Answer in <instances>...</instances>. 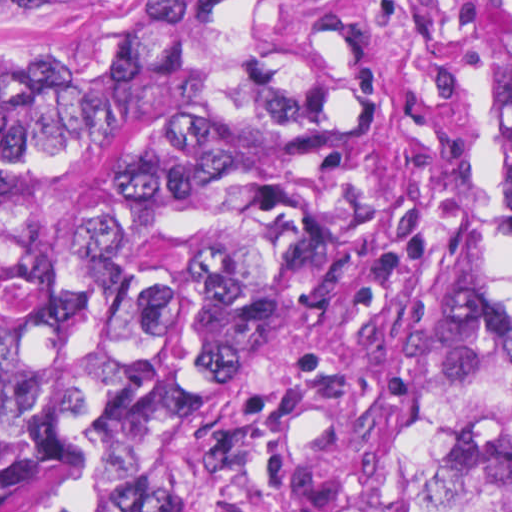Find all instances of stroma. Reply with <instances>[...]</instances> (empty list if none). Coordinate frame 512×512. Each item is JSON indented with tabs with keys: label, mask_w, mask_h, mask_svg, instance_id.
I'll return each mask as SVG.
<instances>
[{
	"label": "stroma",
	"mask_w": 512,
	"mask_h": 512,
	"mask_svg": "<svg viewBox=\"0 0 512 512\" xmlns=\"http://www.w3.org/2000/svg\"><path fill=\"white\" fill-rule=\"evenodd\" d=\"M273 9L299 76L366 93L435 133L442 146L440 223L461 207L512 211L493 197V138L503 104V0H258ZM71 16L1 20V70ZM304 512H365L354 468Z\"/></svg>",
	"instance_id": "35a3bbf8"
}]
</instances>
